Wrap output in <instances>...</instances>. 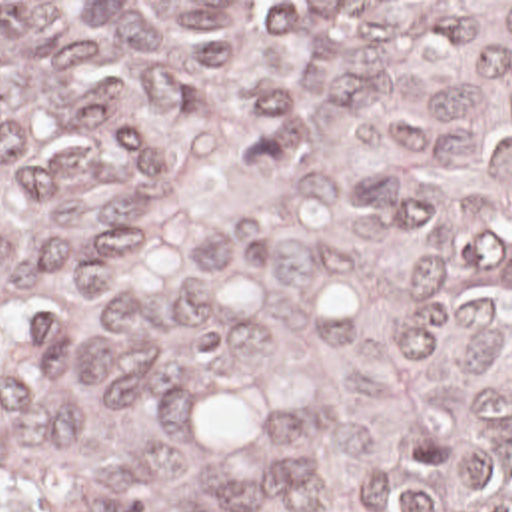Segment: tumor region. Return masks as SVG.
Listing matches in <instances>:
<instances>
[{"instance_id": "e687c5a6", "label": "tumor region", "mask_w": 512, "mask_h": 512, "mask_svg": "<svg viewBox=\"0 0 512 512\" xmlns=\"http://www.w3.org/2000/svg\"><path fill=\"white\" fill-rule=\"evenodd\" d=\"M0 512H512V2H0Z\"/></svg>"}]
</instances>
